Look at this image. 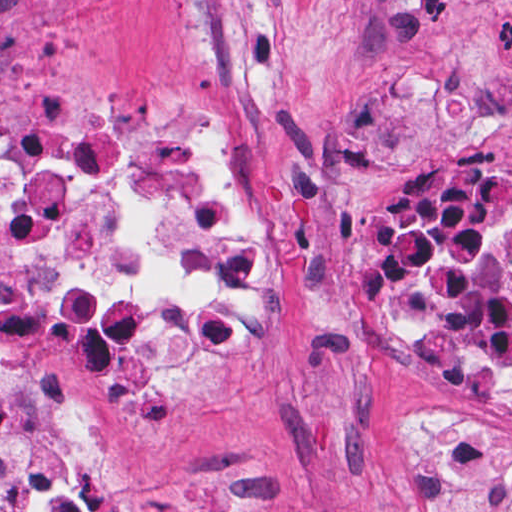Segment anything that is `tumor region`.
<instances>
[{
  "label": "tumor region",
  "mask_w": 512,
  "mask_h": 512,
  "mask_svg": "<svg viewBox=\"0 0 512 512\" xmlns=\"http://www.w3.org/2000/svg\"><path fill=\"white\" fill-rule=\"evenodd\" d=\"M431 512H512V427L458 413L410 411Z\"/></svg>",
  "instance_id": "1"
}]
</instances>
